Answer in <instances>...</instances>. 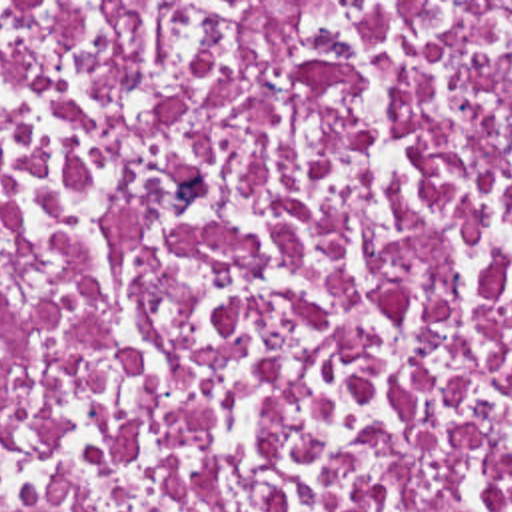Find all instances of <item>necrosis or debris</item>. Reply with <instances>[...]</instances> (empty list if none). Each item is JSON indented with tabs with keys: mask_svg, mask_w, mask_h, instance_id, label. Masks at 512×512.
<instances>
[{
	"mask_svg": "<svg viewBox=\"0 0 512 512\" xmlns=\"http://www.w3.org/2000/svg\"><path fill=\"white\" fill-rule=\"evenodd\" d=\"M0 512H512V2H0Z\"/></svg>",
	"mask_w": 512,
	"mask_h": 512,
	"instance_id": "obj_1",
	"label": "necrosis or debris"
}]
</instances>
